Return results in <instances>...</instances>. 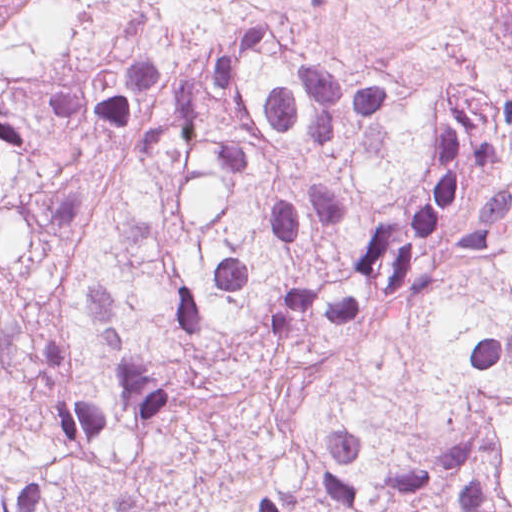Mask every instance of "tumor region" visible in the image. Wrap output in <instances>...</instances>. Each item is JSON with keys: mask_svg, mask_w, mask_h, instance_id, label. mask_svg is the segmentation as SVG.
Returning a JSON list of instances; mask_svg holds the SVG:
<instances>
[{"mask_svg": "<svg viewBox=\"0 0 512 512\" xmlns=\"http://www.w3.org/2000/svg\"><path fill=\"white\" fill-rule=\"evenodd\" d=\"M0 0L2 512H128L294 0Z\"/></svg>", "mask_w": 512, "mask_h": 512, "instance_id": "e687c5a6", "label": "tumor region"}]
</instances>
